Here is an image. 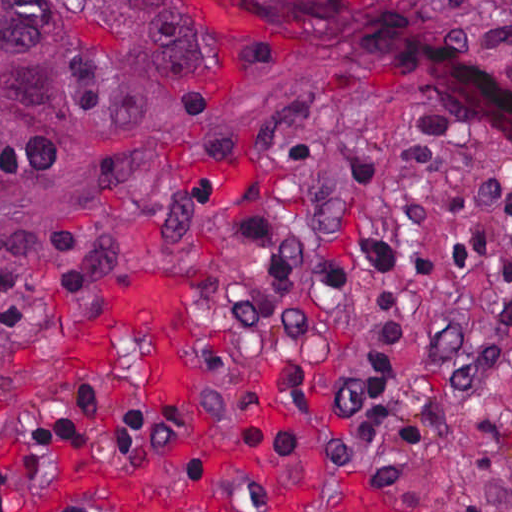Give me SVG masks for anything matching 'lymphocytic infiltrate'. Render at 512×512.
<instances>
[{
  "instance_id": "f902f5d3",
  "label": "lymphocytic infiltrate",
  "mask_w": 512,
  "mask_h": 512,
  "mask_svg": "<svg viewBox=\"0 0 512 512\" xmlns=\"http://www.w3.org/2000/svg\"><path fill=\"white\" fill-rule=\"evenodd\" d=\"M447 134L426 112L403 151L401 178L414 214L405 245L379 233L311 245L240 205L228 209L238 235L285 288H350L373 277L368 318L333 370L314 440L329 458L372 463L391 476L414 475L443 404L501 372L512 335V300L484 318L425 306L432 288L512 282L510 259L481 265L496 238L512 231V170L495 185L458 192L448 212L438 208ZM92 273L90 243L69 231L48 237L39 252L0 259V328L27 325L36 308L73 293ZM204 445L293 459V437L269 420L182 404L132 408L117 394L82 391L65 399L51 429L0 451V512H13L27 487L73 461L161 459L223 486L216 465L199 454Z\"/></svg>"
}]
</instances>
